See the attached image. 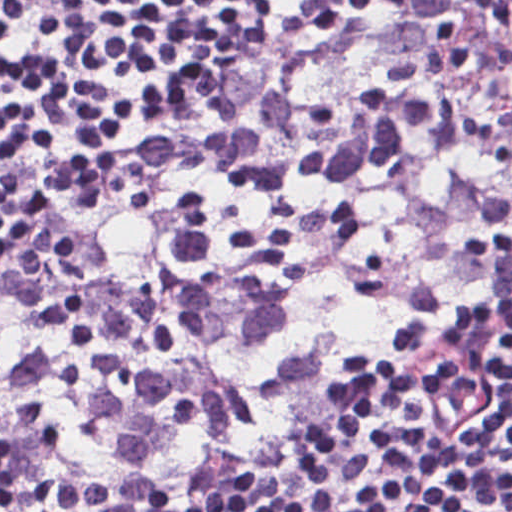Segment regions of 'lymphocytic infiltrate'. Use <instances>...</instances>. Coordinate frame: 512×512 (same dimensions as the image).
<instances>
[{
  "label": "lymphocytic infiltrate",
  "mask_w": 512,
  "mask_h": 512,
  "mask_svg": "<svg viewBox=\"0 0 512 512\" xmlns=\"http://www.w3.org/2000/svg\"><path fill=\"white\" fill-rule=\"evenodd\" d=\"M300 17L98 170L193 58ZM23 241L0 512L271 448L106 512H377L446 445L432 512H512V0H0Z\"/></svg>",
  "instance_id": "1"
}]
</instances>
